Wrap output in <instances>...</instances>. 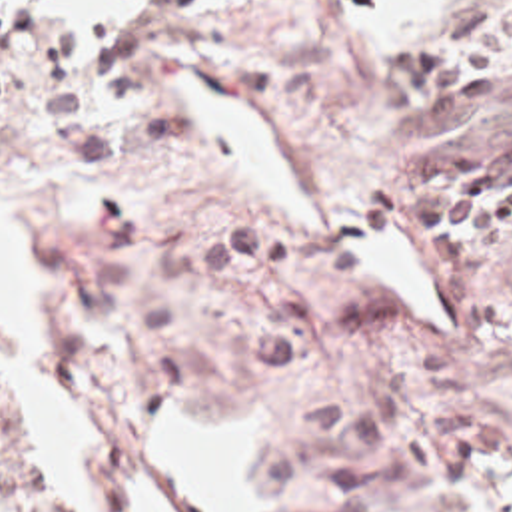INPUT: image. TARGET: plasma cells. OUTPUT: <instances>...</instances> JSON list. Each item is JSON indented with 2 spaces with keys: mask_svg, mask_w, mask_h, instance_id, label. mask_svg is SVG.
<instances>
[{
  "mask_svg": "<svg viewBox=\"0 0 512 512\" xmlns=\"http://www.w3.org/2000/svg\"><path fill=\"white\" fill-rule=\"evenodd\" d=\"M512 67V0H435L373 61V103L393 115H471ZM407 224L445 268L512 242V135L469 148L411 142L401 168Z\"/></svg>",
  "mask_w": 512,
  "mask_h": 512,
  "instance_id": "plasma-cells-1",
  "label": "plasma cells"
}]
</instances>
